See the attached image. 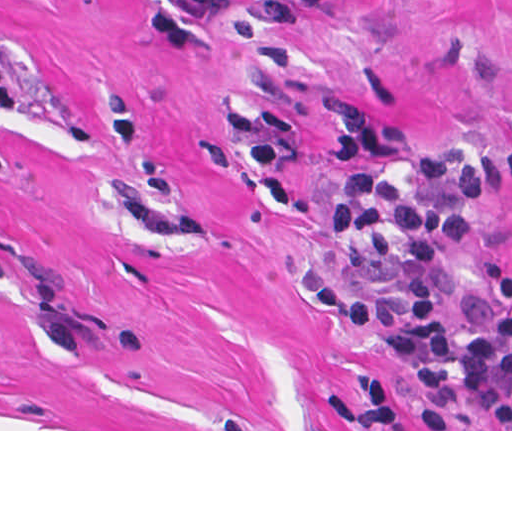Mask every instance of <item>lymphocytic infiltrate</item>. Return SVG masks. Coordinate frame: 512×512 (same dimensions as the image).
I'll return each instance as SVG.
<instances>
[{
  "mask_svg": "<svg viewBox=\"0 0 512 512\" xmlns=\"http://www.w3.org/2000/svg\"><path fill=\"white\" fill-rule=\"evenodd\" d=\"M328 0H258L252 23L286 34L300 14ZM232 0H148L143 12L147 38L166 46H188L202 27L222 19ZM334 172H355L376 163H400L421 175L423 188L409 194L388 177H359L346 183L330 204L325 225L331 236L352 241L377 255L394 247L391 230L405 243L402 263L386 294L361 295L315 270L307 280L311 304L352 328H388L434 316L446 303L438 262L444 242L471 235L470 208L512 186V150L489 157L457 150L421 151L381 123L350 107L335 111V137L323 154ZM496 304L486 309L466 293L460 314L467 338L443 323L419 322L396 329L394 347L414 371L426 401L456 418L459 429H512V273L498 259L481 261Z\"/></svg>",
  "mask_w": 512,
  "mask_h": 512,
  "instance_id": "f902f5d3",
  "label": "lymphocytic infiltrate"
}]
</instances>
